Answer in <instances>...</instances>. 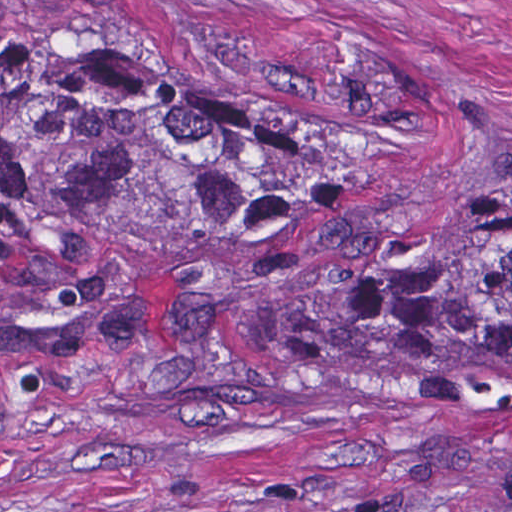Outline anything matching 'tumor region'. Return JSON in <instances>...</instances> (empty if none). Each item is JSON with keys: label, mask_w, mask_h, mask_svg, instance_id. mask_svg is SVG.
Here are the masks:
<instances>
[{"label": "tumor region", "mask_w": 512, "mask_h": 512, "mask_svg": "<svg viewBox=\"0 0 512 512\" xmlns=\"http://www.w3.org/2000/svg\"><path fill=\"white\" fill-rule=\"evenodd\" d=\"M349 132L122 47L1 39V340L65 334L96 280L171 256L281 332L512 359V200L380 282H340L321 229Z\"/></svg>", "instance_id": "obj_1"}]
</instances>
